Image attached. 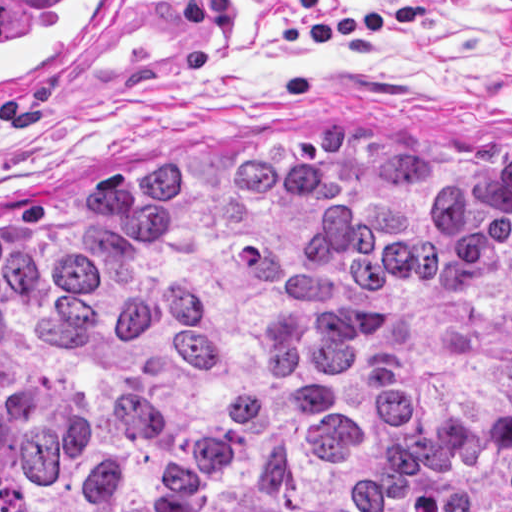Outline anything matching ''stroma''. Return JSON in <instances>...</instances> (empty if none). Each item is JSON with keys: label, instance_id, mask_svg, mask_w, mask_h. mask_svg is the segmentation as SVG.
Listing matches in <instances>:
<instances>
[{"label": "stroma", "instance_id": "stroma-1", "mask_svg": "<svg viewBox=\"0 0 512 512\" xmlns=\"http://www.w3.org/2000/svg\"><path fill=\"white\" fill-rule=\"evenodd\" d=\"M233 23L187 25L186 0H129L111 55L59 97H0V234L83 195L134 155H213L279 137H392L433 159H512V4L423 0L429 18L338 45L281 49L278 22L399 0H229Z\"/></svg>", "mask_w": 512, "mask_h": 512}]
</instances>
